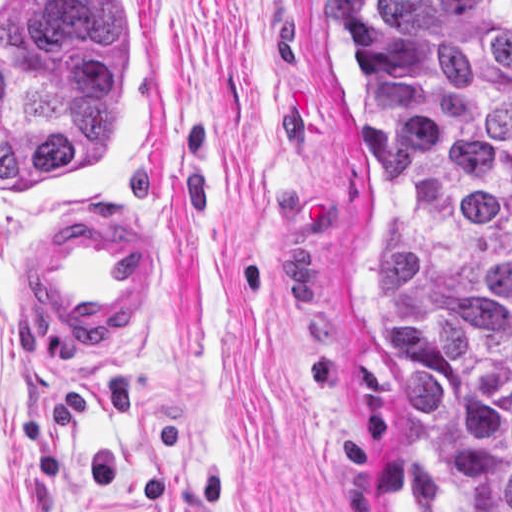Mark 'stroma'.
I'll return each mask as SVG.
<instances>
[{"mask_svg": "<svg viewBox=\"0 0 512 512\" xmlns=\"http://www.w3.org/2000/svg\"><path fill=\"white\" fill-rule=\"evenodd\" d=\"M149 1L163 144L97 217L0 230V512H427L379 339L387 191L337 1ZM80 221L161 233L134 324L45 291Z\"/></svg>", "mask_w": 512, "mask_h": 512, "instance_id": "stroma-1", "label": "stroma"}]
</instances>
